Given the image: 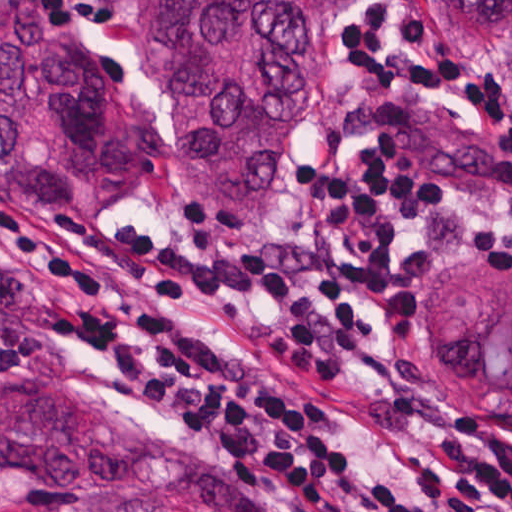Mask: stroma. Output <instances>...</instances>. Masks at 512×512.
<instances>
[{
    "mask_svg": "<svg viewBox=\"0 0 512 512\" xmlns=\"http://www.w3.org/2000/svg\"><path fill=\"white\" fill-rule=\"evenodd\" d=\"M365 1L337 22L329 33L320 84L301 130L287 188L278 205L258 224L229 226L210 215L184 183L169 149L158 153L139 179L115 189L109 199L90 208L27 211L3 181H0V203L31 222L54 226L67 239L69 235L102 226L136 225L147 227L159 238L199 239L223 246L263 241H314L321 243L328 252L355 261V243L337 238L329 229L325 208L304 190L302 170L310 164L347 168L366 146V130L335 151L328 141V128L345 104L355 97L365 96L373 88L339 47L341 34L355 24ZM96 2L107 14V27L94 29L73 25L69 31L72 35H68L95 60L121 109L167 133L166 103L172 94V81L149 71L145 62L151 0ZM380 2L394 31L391 42L382 47L386 51L407 48L417 51L397 25V14L404 8H414L424 18L426 37L439 52L461 57L470 67L488 68L512 94V52H477L463 44L444 29L433 0ZM414 238L425 249L428 262L426 269L408 283L414 301L413 312L409 317H375L377 338L356 354L344 377L336 381L314 380L264 345L254 326L265 335L284 322V312L279 305L191 297L171 298L161 303L181 318L235 342L276 366L324 416L333 419L342 439L362 452L385 478L420 495L412 467L416 459L438 457L435 437L469 419H484L499 434L512 439V410H467L460 404V397L439 368L430 362L419 340V293L443 265L461 260H496L511 274L512 265L462 228L442 218H417ZM354 307L369 313L359 299ZM452 383L462 399L473 401ZM54 387H83L163 442L223 468L257 478L245 466L182 432L138 392L105 370L68 331L44 322L42 357L15 376L0 381V412L29 391ZM265 483L308 512H337L324 503ZM27 490L0 481V512H8Z\"/></svg>",
    "mask_w": 512,
    "mask_h": 512,
    "instance_id": "stroma-1",
    "label": "stroma"
}]
</instances>
